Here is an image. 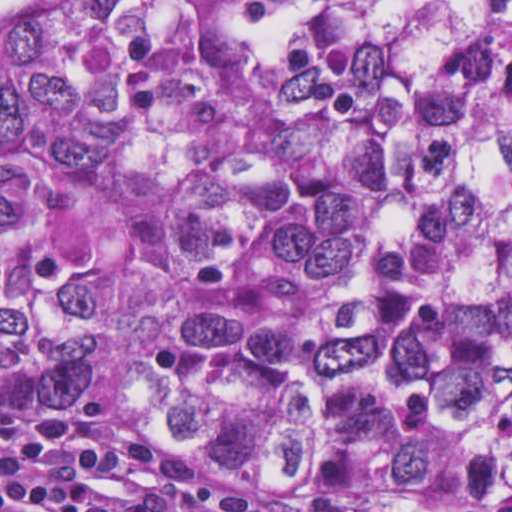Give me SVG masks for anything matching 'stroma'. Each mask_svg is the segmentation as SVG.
Listing matches in <instances>:
<instances>
[{
	"label": "stroma",
	"instance_id": "35a3bbf8",
	"mask_svg": "<svg viewBox=\"0 0 512 512\" xmlns=\"http://www.w3.org/2000/svg\"><path fill=\"white\" fill-rule=\"evenodd\" d=\"M233 16L255 36L282 47L293 36H328L342 40L351 0H229ZM87 398L82 402H95ZM309 493H333L400 512H512V502H458L424 497H362L348 478L332 480Z\"/></svg>",
	"mask_w": 512,
	"mask_h": 512
}]
</instances>
